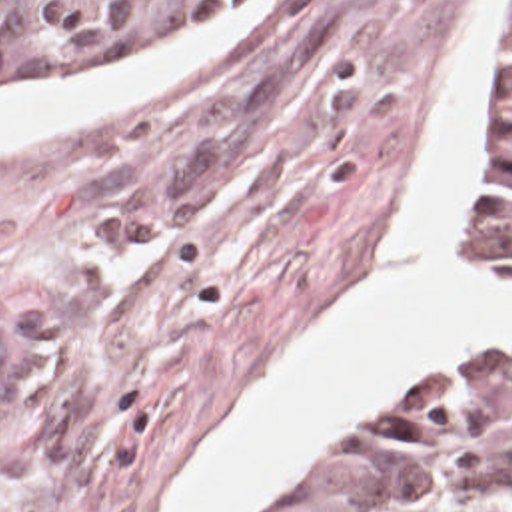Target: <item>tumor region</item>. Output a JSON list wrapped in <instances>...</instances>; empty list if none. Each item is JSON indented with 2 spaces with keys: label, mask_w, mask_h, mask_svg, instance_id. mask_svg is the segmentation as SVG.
<instances>
[{
  "label": "tumor region",
  "mask_w": 512,
  "mask_h": 512,
  "mask_svg": "<svg viewBox=\"0 0 512 512\" xmlns=\"http://www.w3.org/2000/svg\"><path fill=\"white\" fill-rule=\"evenodd\" d=\"M233 0H0V95L59 89ZM481 245L512 269V35ZM271 512H512V345L455 353L307 464Z\"/></svg>",
  "instance_id": "tumor-region-1"
}]
</instances>
